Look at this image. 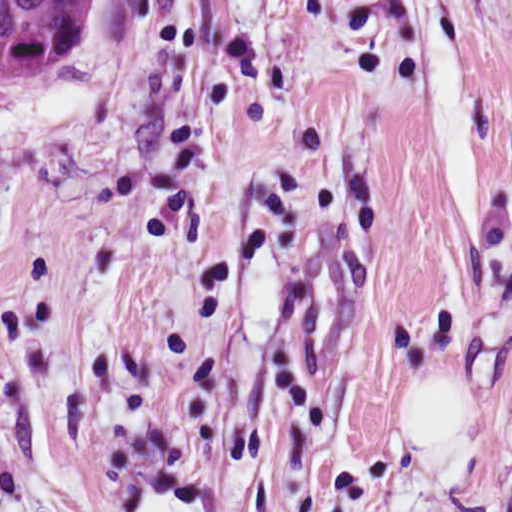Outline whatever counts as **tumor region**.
I'll return each mask as SVG.
<instances>
[{
  "instance_id": "e687c5a6",
  "label": "tumor region",
  "mask_w": 512,
  "mask_h": 512,
  "mask_svg": "<svg viewBox=\"0 0 512 512\" xmlns=\"http://www.w3.org/2000/svg\"><path fill=\"white\" fill-rule=\"evenodd\" d=\"M96 0H0V77L64 68L84 48Z\"/></svg>"
}]
</instances>
